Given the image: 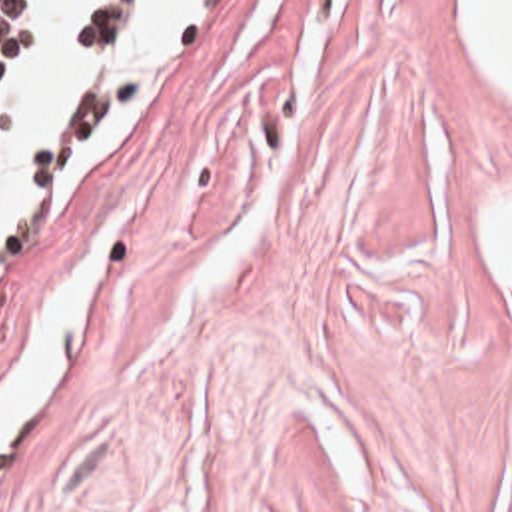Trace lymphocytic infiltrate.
Instances as JSON below:
<instances>
[{
	"mask_svg": "<svg viewBox=\"0 0 512 512\" xmlns=\"http://www.w3.org/2000/svg\"><path fill=\"white\" fill-rule=\"evenodd\" d=\"M147 0H99L83 24L77 48L79 52H99L101 44L125 26ZM37 34V16L33 0H0V108L13 70L23 50ZM45 142L31 154L29 168L35 164Z\"/></svg>",
	"mask_w": 512,
	"mask_h": 512,
	"instance_id": "f902f5d3",
	"label": "lymphocytic infiltrate"
}]
</instances>
